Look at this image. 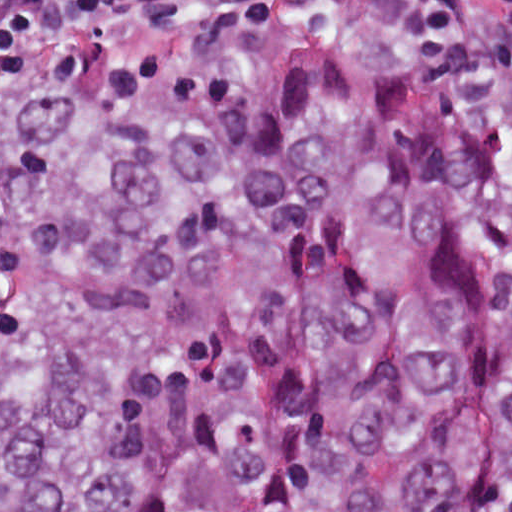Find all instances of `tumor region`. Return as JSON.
I'll return each mask as SVG.
<instances>
[{"mask_svg": "<svg viewBox=\"0 0 512 512\" xmlns=\"http://www.w3.org/2000/svg\"><path fill=\"white\" fill-rule=\"evenodd\" d=\"M0 512H512V76L321 16L24 53Z\"/></svg>", "mask_w": 512, "mask_h": 512, "instance_id": "tumor-region-1", "label": "tumor region"}]
</instances>
